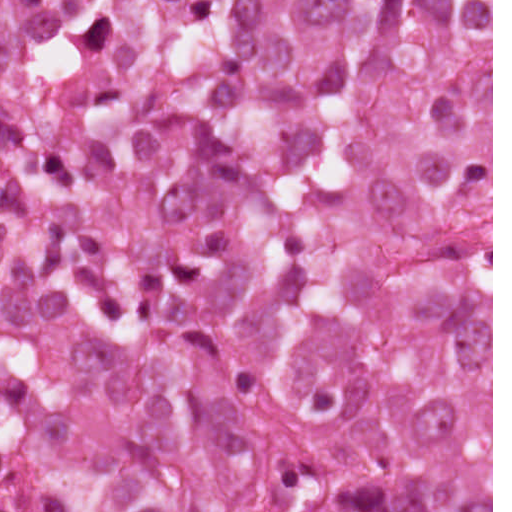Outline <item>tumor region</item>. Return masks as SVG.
I'll return each instance as SVG.
<instances>
[{"label":"tumor region","mask_w":512,"mask_h":512,"mask_svg":"<svg viewBox=\"0 0 512 512\" xmlns=\"http://www.w3.org/2000/svg\"><path fill=\"white\" fill-rule=\"evenodd\" d=\"M0 512H491V0H0Z\"/></svg>","instance_id":"tumor-region-1"}]
</instances>
